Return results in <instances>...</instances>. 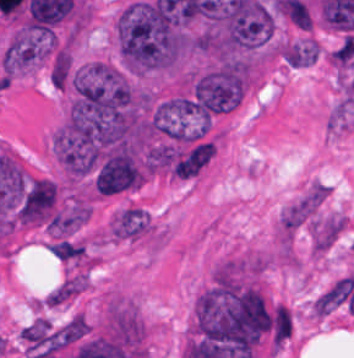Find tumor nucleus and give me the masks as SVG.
Segmentation results:
<instances>
[{
  "label": "tumor nucleus",
  "instance_id": "obj_1",
  "mask_svg": "<svg viewBox=\"0 0 354 358\" xmlns=\"http://www.w3.org/2000/svg\"><path fill=\"white\" fill-rule=\"evenodd\" d=\"M321 49L310 36L282 39L279 42L278 56L288 66H307L316 61Z\"/></svg>",
  "mask_w": 354,
  "mask_h": 358
}]
</instances>
